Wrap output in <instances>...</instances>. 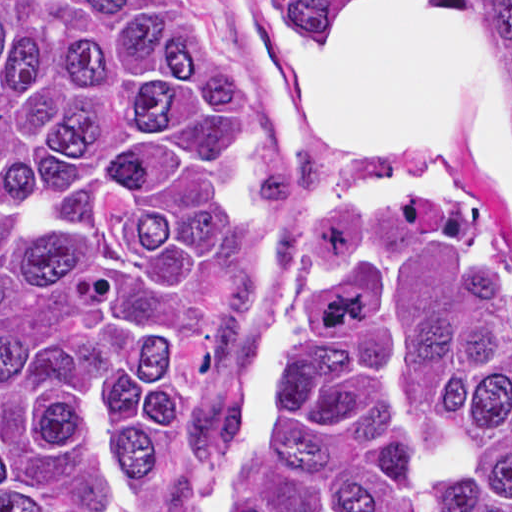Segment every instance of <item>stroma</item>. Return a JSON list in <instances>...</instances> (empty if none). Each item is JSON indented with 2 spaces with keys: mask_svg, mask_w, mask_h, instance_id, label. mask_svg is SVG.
I'll use <instances>...</instances> for the list:
<instances>
[{
  "mask_svg": "<svg viewBox=\"0 0 512 512\" xmlns=\"http://www.w3.org/2000/svg\"><path fill=\"white\" fill-rule=\"evenodd\" d=\"M0 1H183L207 29L226 64L251 90L253 110L244 133L241 155L249 175L256 164L277 165L287 154L308 147L321 160L317 193L287 212L266 241L261 266L251 284L247 327L235 376L245 404L267 376L277 354L296 296V261L310 216L341 194L352 191L446 189L470 200L479 215V192L471 166L468 131L445 146V165L423 183L390 189L372 185L357 172L339 165L299 122L269 58L264 30L257 13L270 0H0ZM358 1L359 0H281ZM512 1V0H490ZM354 5L339 21L340 41L349 26ZM174 463V437L140 483L124 512H159ZM221 470L196 489L186 512H211Z\"/></svg>",
  "mask_w": 512,
  "mask_h": 512,
  "instance_id": "stroma-1",
  "label": "stroma"
}]
</instances>
